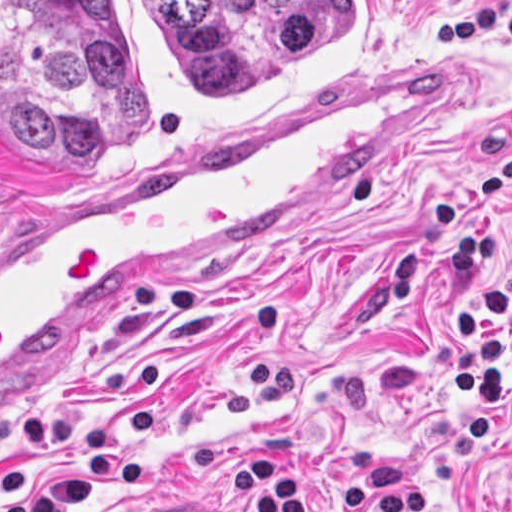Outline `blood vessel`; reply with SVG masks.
I'll list each match as a JSON object with an SVG mask.
<instances>
[{"label": "blood vessel", "instance_id": "1", "mask_svg": "<svg viewBox=\"0 0 512 512\" xmlns=\"http://www.w3.org/2000/svg\"><path fill=\"white\" fill-rule=\"evenodd\" d=\"M493 67L390 75L201 161L90 187L1 239V366L71 343L315 192L423 142Z\"/></svg>", "mask_w": 512, "mask_h": 512}]
</instances>
